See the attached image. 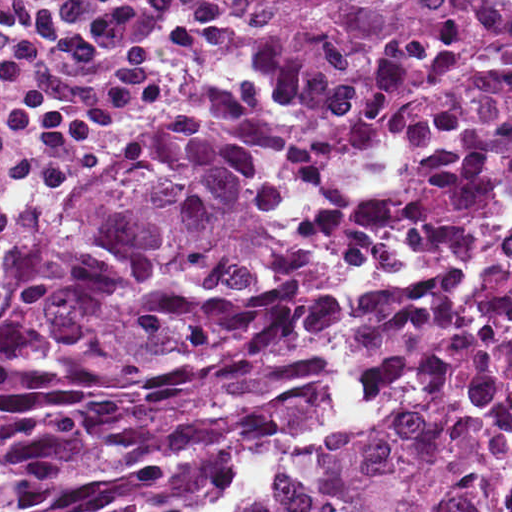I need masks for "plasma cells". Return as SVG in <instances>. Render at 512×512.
Wrapping results in <instances>:
<instances>
[{"instance_id": "obj_1", "label": "plasma cells", "mask_w": 512, "mask_h": 512, "mask_svg": "<svg viewBox=\"0 0 512 512\" xmlns=\"http://www.w3.org/2000/svg\"><path fill=\"white\" fill-rule=\"evenodd\" d=\"M245 0H0V256L107 133L185 96Z\"/></svg>"}]
</instances>
